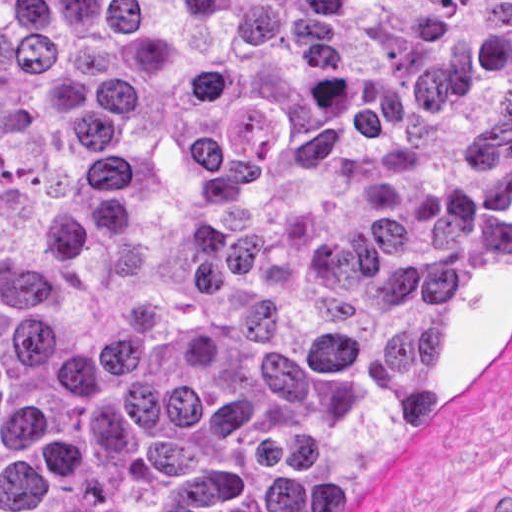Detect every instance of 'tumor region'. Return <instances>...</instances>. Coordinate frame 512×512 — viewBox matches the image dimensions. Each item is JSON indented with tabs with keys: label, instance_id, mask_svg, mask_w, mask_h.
<instances>
[{
	"label": "tumor region",
	"instance_id": "tumor-region-1",
	"mask_svg": "<svg viewBox=\"0 0 512 512\" xmlns=\"http://www.w3.org/2000/svg\"><path fill=\"white\" fill-rule=\"evenodd\" d=\"M511 243L512 1H0V512H341Z\"/></svg>",
	"mask_w": 512,
	"mask_h": 512
}]
</instances>
